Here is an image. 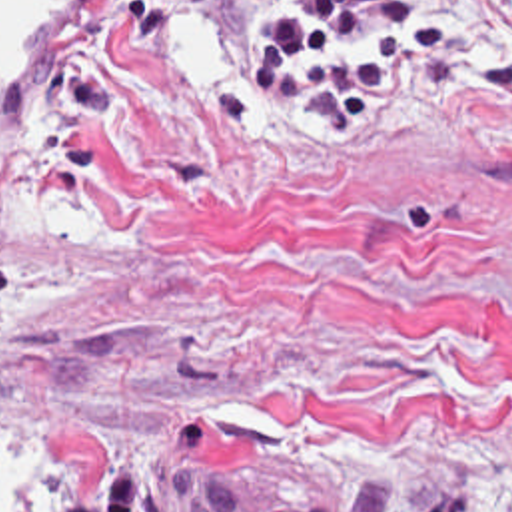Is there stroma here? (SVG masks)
Returning a JSON list of instances; mask_svg holds the SVG:
<instances>
[{"instance_id": "35a3bbf8", "label": "stroma", "mask_w": 512, "mask_h": 512, "mask_svg": "<svg viewBox=\"0 0 512 512\" xmlns=\"http://www.w3.org/2000/svg\"><path fill=\"white\" fill-rule=\"evenodd\" d=\"M337 127L253 121L291 0H89L0 169L11 512H512V71L442 0Z\"/></svg>"}]
</instances>
